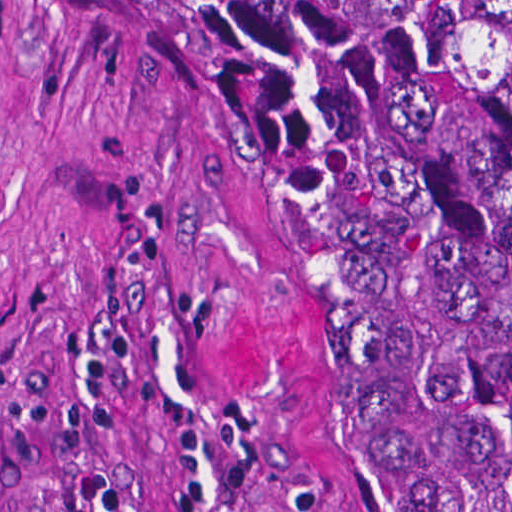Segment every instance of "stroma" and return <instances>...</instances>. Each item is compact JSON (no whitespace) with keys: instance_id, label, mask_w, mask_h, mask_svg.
I'll return each mask as SVG.
<instances>
[{"instance_id":"1","label":"stroma","mask_w":512,"mask_h":512,"mask_svg":"<svg viewBox=\"0 0 512 512\" xmlns=\"http://www.w3.org/2000/svg\"><path fill=\"white\" fill-rule=\"evenodd\" d=\"M0 512H415L333 232L125 0H0Z\"/></svg>"}]
</instances>
